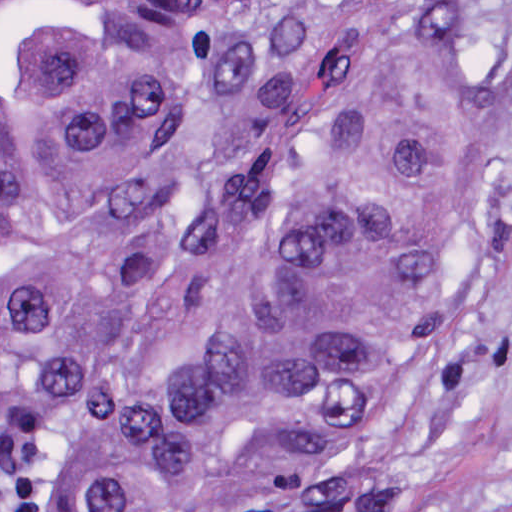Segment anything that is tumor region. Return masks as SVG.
<instances>
[{
	"label": "tumor region",
	"instance_id": "tumor-region-1",
	"mask_svg": "<svg viewBox=\"0 0 512 512\" xmlns=\"http://www.w3.org/2000/svg\"><path fill=\"white\" fill-rule=\"evenodd\" d=\"M479 1H0V429L182 511L384 433L512 161Z\"/></svg>",
	"mask_w": 512,
	"mask_h": 512
}]
</instances>
